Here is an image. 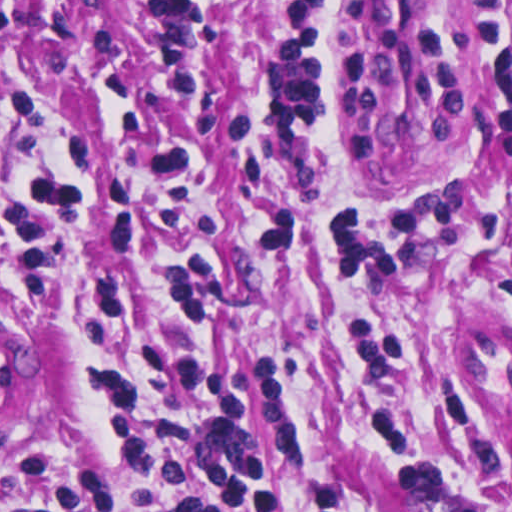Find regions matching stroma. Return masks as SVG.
Segmentation results:
<instances>
[{"instance_id":"stroma-1","label":"stroma","mask_w":512,"mask_h":512,"mask_svg":"<svg viewBox=\"0 0 512 512\" xmlns=\"http://www.w3.org/2000/svg\"><path fill=\"white\" fill-rule=\"evenodd\" d=\"M354 1H448L479 112L465 165L420 170L379 151L342 56ZM8 63L88 74L124 97L60 299L21 294L12 196L88 122L91 85L47 87L38 129L0 145V335L25 356L24 397L0 398V479L32 457L97 472L114 512L185 502L128 470L103 399L106 372L171 328L226 372L273 476L276 433L272 512H512V0H0ZM134 95L174 120L133 129ZM198 137L216 166L187 241L113 252L122 168ZM255 198L289 216L250 219ZM249 221L274 265L269 300ZM188 245L217 266L214 316L173 323L156 301L89 334L102 279H160Z\"/></svg>"}]
</instances>
